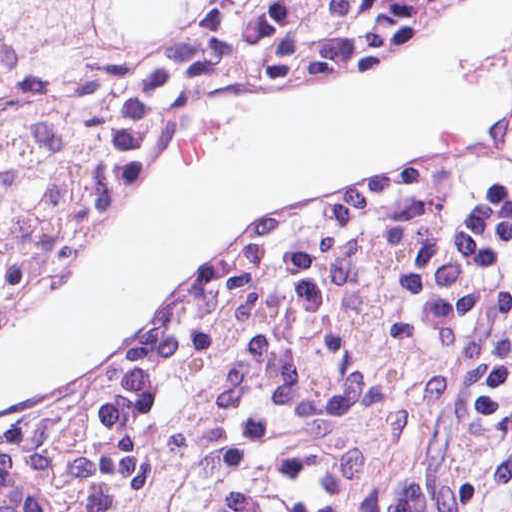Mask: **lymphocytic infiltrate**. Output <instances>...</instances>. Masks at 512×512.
Masks as SVG:
<instances>
[{
	"label": "lymphocytic infiltrate",
	"mask_w": 512,
	"mask_h": 512,
	"mask_svg": "<svg viewBox=\"0 0 512 512\" xmlns=\"http://www.w3.org/2000/svg\"><path fill=\"white\" fill-rule=\"evenodd\" d=\"M384 1H229L150 61L119 71L90 228L185 139L222 87L297 61ZM512 278V80L461 169L293 221L218 267L163 332L92 381L75 449L116 391L174 336L242 319H335L405 456Z\"/></svg>",
	"instance_id": "1"
}]
</instances>
